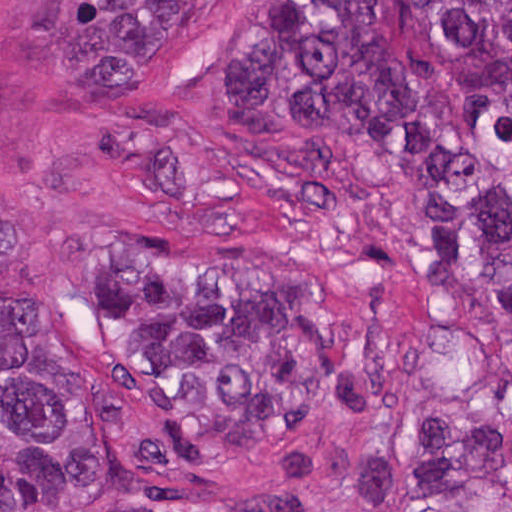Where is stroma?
I'll use <instances>...</instances> for the list:
<instances>
[{"instance_id": "35a3bbf8", "label": "stroma", "mask_w": 512, "mask_h": 512, "mask_svg": "<svg viewBox=\"0 0 512 512\" xmlns=\"http://www.w3.org/2000/svg\"><path fill=\"white\" fill-rule=\"evenodd\" d=\"M247 1L0 0V328L92 356L125 256L254 247L326 272L342 374L318 429L386 444L457 413L512 454V326L436 287L388 174L350 151L316 200L252 160L233 84ZM80 512L364 511L337 482L296 494L260 450Z\"/></svg>"}]
</instances>
